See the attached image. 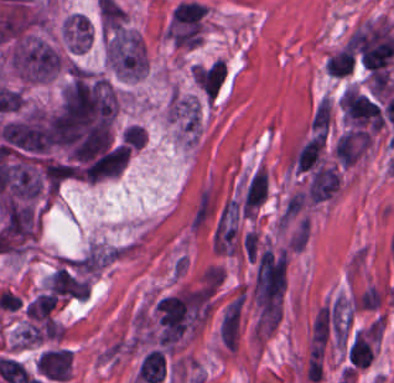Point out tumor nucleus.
<instances>
[{
  "mask_svg": "<svg viewBox=\"0 0 394 383\" xmlns=\"http://www.w3.org/2000/svg\"><path fill=\"white\" fill-rule=\"evenodd\" d=\"M65 36L74 51H86L92 38V25L85 15L74 13L65 22Z\"/></svg>",
  "mask_w": 394,
  "mask_h": 383,
  "instance_id": "tumor-nucleus-3",
  "label": "tumor nucleus"
},
{
  "mask_svg": "<svg viewBox=\"0 0 394 383\" xmlns=\"http://www.w3.org/2000/svg\"><path fill=\"white\" fill-rule=\"evenodd\" d=\"M45 288L56 300H63L85 295L89 285L76 263L62 262L49 276Z\"/></svg>",
  "mask_w": 394,
  "mask_h": 383,
  "instance_id": "tumor-nucleus-2",
  "label": "tumor nucleus"
},
{
  "mask_svg": "<svg viewBox=\"0 0 394 383\" xmlns=\"http://www.w3.org/2000/svg\"><path fill=\"white\" fill-rule=\"evenodd\" d=\"M106 57L127 78L144 76V40L127 28H121L108 36Z\"/></svg>",
  "mask_w": 394,
  "mask_h": 383,
  "instance_id": "tumor-nucleus-1",
  "label": "tumor nucleus"
}]
</instances>
